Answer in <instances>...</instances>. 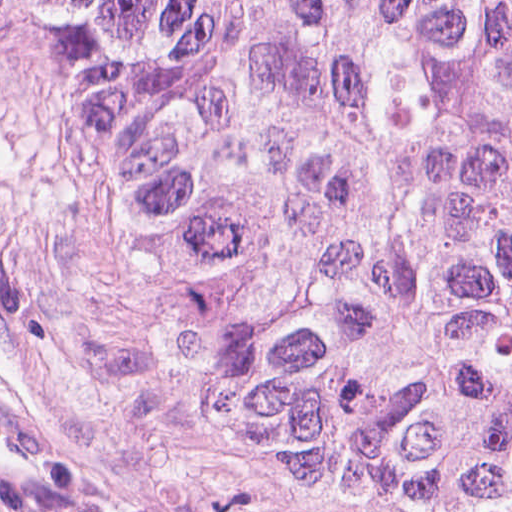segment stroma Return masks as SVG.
<instances>
[{
    "instance_id": "obj_1",
    "label": "stroma",
    "mask_w": 512,
    "mask_h": 512,
    "mask_svg": "<svg viewBox=\"0 0 512 512\" xmlns=\"http://www.w3.org/2000/svg\"><path fill=\"white\" fill-rule=\"evenodd\" d=\"M0 512H356L198 414L0 66Z\"/></svg>"
}]
</instances>
